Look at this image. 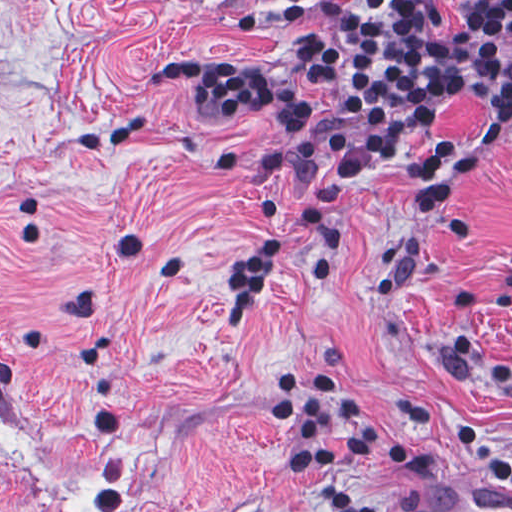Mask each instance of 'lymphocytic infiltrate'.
<instances>
[{"instance_id": "f902f5d3", "label": "lymphocytic infiltrate", "mask_w": 512, "mask_h": 512, "mask_svg": "<svg viewBox=\"0 0 512 512\" xmlns=\"http://www.w3.org/2000/svg\"><path fill=\"white\" fill-rule=\"evenodd\" d=\"M300 79L325 96L328 119L317 122L296 95L254 65L237 60H169L158 78L190 88L208 123L274 116L282 146L229 147L220 164L272 184H296L305 202H267L266 219L297 220L318 239L311 280L330 282L337 257L331 202L380 164L398 158L410 167L404 188L422 233L446 211L474 170L471 150L435 139L452 95L485 106V156L512 124V0H462L441 38L439 0H355L340 5L333 22L290 50ZM459 210L453 244L484 237L469 230ZM286 239H269L231 272L225 324H250L267 292V277ZM512 402V356L498 366ZM269 416L289 425L290 473L306 481L318 512H419L370 496L358 466L421 462L392 430H423L460 443L486 479L512 488V453L492 445L483 411L432 397L376 395L313 371L293 370L272 386Z\"/></svg>"}]
</instances>
